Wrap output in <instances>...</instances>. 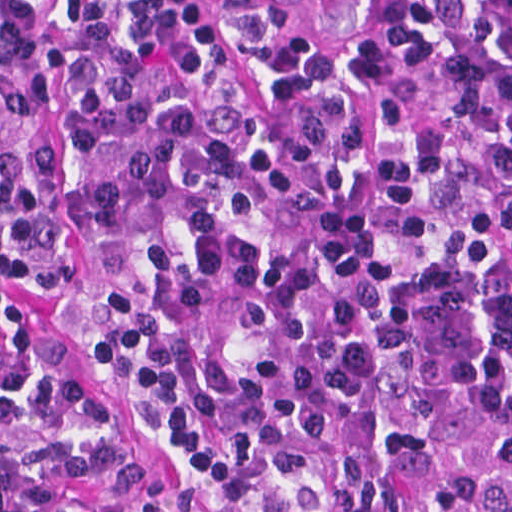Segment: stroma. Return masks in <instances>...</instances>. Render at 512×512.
<instances>
[{"mask_svg":"<svg viewBox=\"0 0 512 512\" xmlns=\"http://www.w3.org/2000/svg\"><path fill=\"white\" fill-rule=\"evenodd\" d=\"M279 2L304 29L344 39L358 31L374 0H236ZM68 292L61 285H29L0 259V317L25 332L38 330L63 348L57 392H82L113 420L131 453L160 467L176 480L177 459L160 433L127 415L119 384L98 350L72 325L62 311Z\"/></svg>","mask_w":512,"mask_h":512,"instance_id":"obj_1","label":"stroma"}]
</instances>
